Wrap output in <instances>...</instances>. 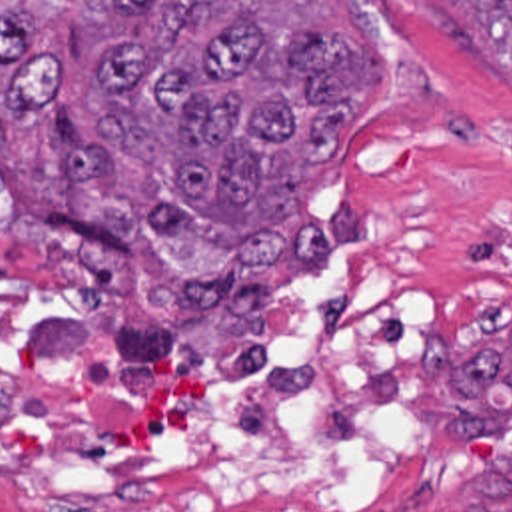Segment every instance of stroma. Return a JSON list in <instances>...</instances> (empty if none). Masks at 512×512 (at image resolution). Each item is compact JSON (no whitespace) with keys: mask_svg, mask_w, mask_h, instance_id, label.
Returning <instances> with one entry per match:
<instances>
[{"mask_svg":"<svg viewBox=\"0 0 512 512\" xmlns=\"http://www.w3.org/2000/svg\"><path fill=\"white\" fill-rule=\"evenodd\" d=\"M261 12L375 42V94L337 156L309 180V214L331 228L337 210L349 212L355 232L349 248L323 262L353 264L437 304V356L415 433V499L403 509L347 512H465L483 467L507 465L512 479V421L453 419L447 387L481 346L512 340V84L479 48L457 0H263ZM0 266L103 308L155 314L207 350L263 354L237 352L225 318L169 322L127 270L99 294L10 228L0 232ZM313 268L289 254L271 268L261 320L267 352L281 292ZM485 481L512 505L511 481Z\"/></svg>","mask_w":512,"mask_h":512,"instance_id":"35a3bbf8","label":"stroma"}]
</instances>
